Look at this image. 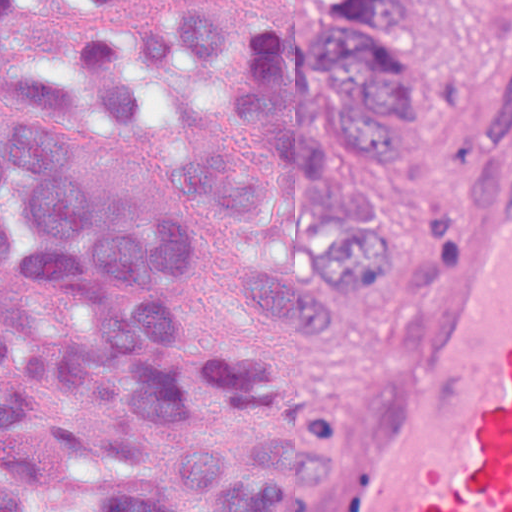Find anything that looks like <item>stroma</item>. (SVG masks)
<instances>
[{
    "instance_id": "35a3bbf8",
    "label": "stroma",
    "mask_w": 512,
    "mask_h": 512,
    "mask_svg": "<svg viewBox=\"0 0 512 512\" xmlns=\"http://www.w3.org/2000/svg\"><path fill=\"white\" fill-rule=\"evenodd\" d=\"M322 0H26L74 35H142L202 13L225 18L241 39L286 41ZM497 0H423L436 38L386 173L348 136L326 128L340 163L372 200L336 274L290 335L255 304L236 260L284 264L304 256L329 217L286 201L244 223L178 173V150L246 142L267 158L274 138L235 113L212 80L172 75L158 119L142 135L103 114H61L90 153L96 185L178 221L184 278L173 284L180 317L247 343L271 365L283 411L336 439L361 414L400 352L427 291L433 258L454 217L479 121L495 38ZM62 43H19L0 61V97L14 68L59 71Z\"/></svg>"
}]
</instances>
